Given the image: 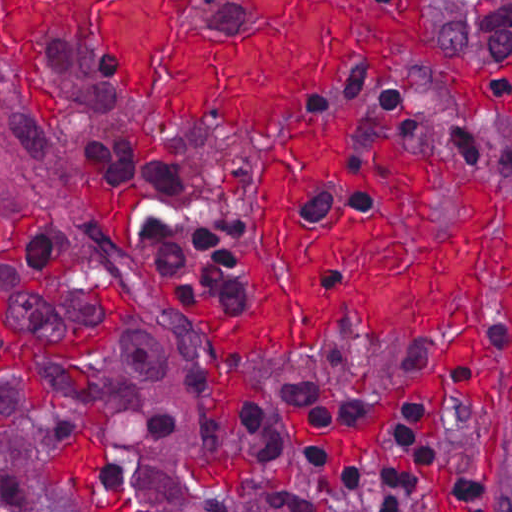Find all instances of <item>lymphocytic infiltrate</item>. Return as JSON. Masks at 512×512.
<instances>
[{
	"label": "lymphocytic infiltrate",
	"mask_w": 512,
	"mask_h": 512,
	"mask_svg": "<svg viewBox=\"0 0 512 512\" xmlns=\"http://www.w3.org/2000/svg\"><path fill=\"white\" fill-rule=\"evenodd\" d=\"M99 164L111 177L147 186L141 237L152 261L189 269L225 303L244 307L236 261L249 232L243 212L214 206L194 177L140 145L105 142ZM420 413V406L404 408L392 422L401 453L396 466H358L342 477L339 491L327 493L320 454L287 444L269 414L250 405L240 437L263 504L196 512H409L422 499H436L450 512H512V492L443 438L424 433L417 451Z\"/></svg>",
	"instance_id": "lymphocytic-infiltrate-1"
}]
</instances>
